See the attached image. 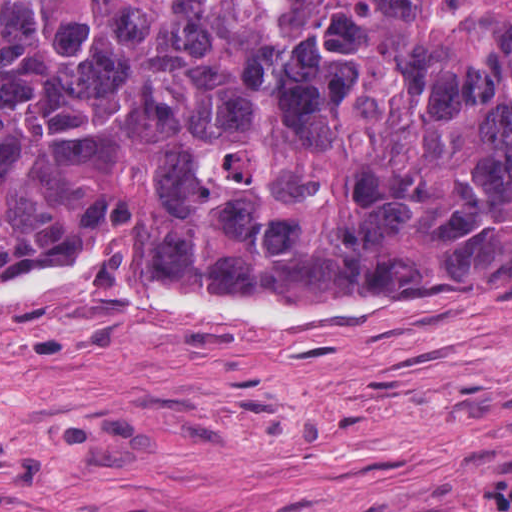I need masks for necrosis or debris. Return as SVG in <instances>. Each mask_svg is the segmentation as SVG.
<instances>
[{
    "label": "necrosis or debris",
    "instance_id": "necrosis-or-debris-1",
    "mask_svg": "<svg viewBox=\"0 0 512 512\" xmlns=\"http://www.w3.org/2000/svg\"><path fill=\"white\" fill-rule=\"evenodd\" d=\"M424 512H512V480L447 497Z\"/></svg>",
    "mask_w": 512,
    "mask_h": 512
}]
</instances>
